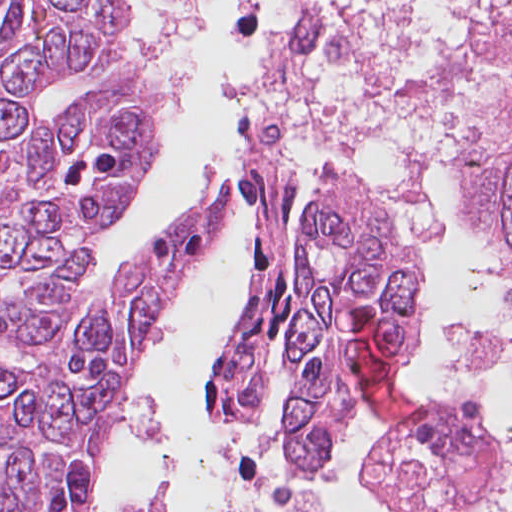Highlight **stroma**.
<instances>
[{"label":"stroma","mask_w":512,"mask_h":512,"mask_svg":"<svg viewBox=\"0 0 512 512\" xmlns=\"http://www.w3.org/2000/svg\"><path fill=\"white\" fill-rule=\"evenodd\" d=\"M318 185H319V182L304 186L305 194H306V197H307L310 209H311V207H312V205L314 203V200L316 198V189H317ZM473 215H474V217H475V219H476V221H477V223H478L482 233L484 234V236L491 243V245L494 247V249L501 255V257L504 259V261L509 266L512 267V253L507 251V250H505V249H503V248H501V247H499V246H497L492 241H490L488 239L484 229H483V226H482V223H481V220H480V195L478 197L476 206L474 208ZM419 348H421V323H420V345L417 347V349L415 351H417ZM412 355L407 357L402 363H400V373H401V375H403V377L406 380V382L408 383L412 393L414 394V396L416 397L417 401L419 402V404H420V413H422L424 410H426L430 406L428 405V396H427L424 388L415 379V377L412 375V373L410 371L408 363H409ZM383 415H385V414L383 413ZM385 416H387V415H385ZM409 424L410 423H408V425Z\"/></svg>","instance_id":"obj_1"}]
</instances>
